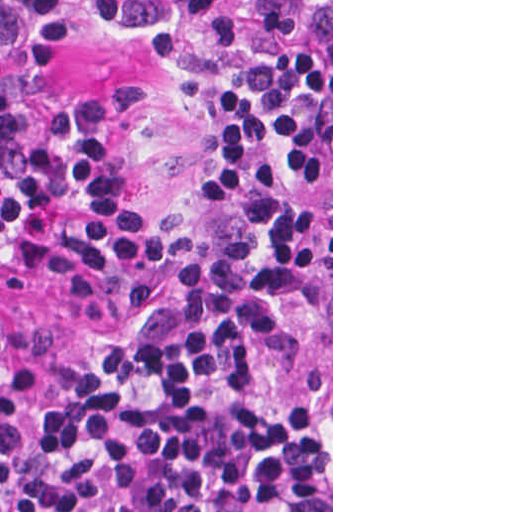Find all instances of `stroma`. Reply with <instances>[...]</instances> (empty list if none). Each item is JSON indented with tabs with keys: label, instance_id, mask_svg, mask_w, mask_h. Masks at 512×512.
I'll list each match as a JSON object with an SVG mask.
<instances>
[{
	"label": "stroma",
	"instance_id": "obj_1",
	"mask_svg": "<svg viewBox=\"0 0 512 512\" xmlns=\"http://www.w3.org/2000/svg\"><path fill=\"white\" fill-rule=\"evenodd\" d=\"M310 49L331 50V512H333V0H298ZM140 91L128 127L130 184L148 205H179L207 171L205 118L177 72L156 49L124 34H81L61 43L55 98L82 109ZM0 384L30 360L78 358L81 315L58 278L0 271Z\"/></svg>",
	"mask_w": 512,
	"mask_h": 512
}]
</instances>
